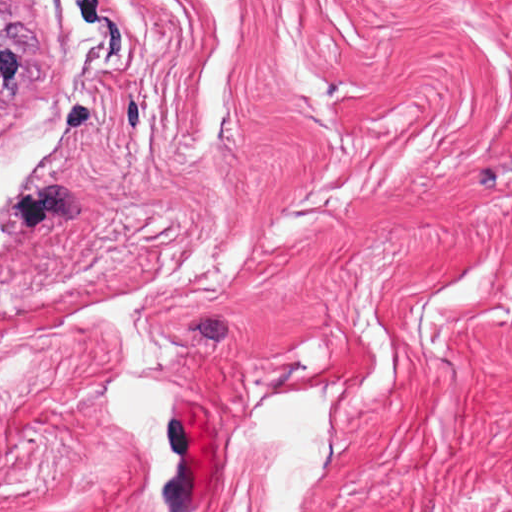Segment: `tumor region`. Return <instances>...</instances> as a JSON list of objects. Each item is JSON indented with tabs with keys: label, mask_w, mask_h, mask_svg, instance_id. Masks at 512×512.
<instances>
[{
	"label": "tumor region",
	"mask_w": 512,
	"mask_h": 512,
	"mask_svg": "<svg viewBox=\"0 0 512 512\" xmlns=\"http://www.w3.org/2000/svg\"><path fill=\"white\" fill-rule=\"evenodd\" d=\"M33 31L0 0V101L29 85L27 54Z\"/></svg>",
	"instance_id": "1"
}]
</instances>
